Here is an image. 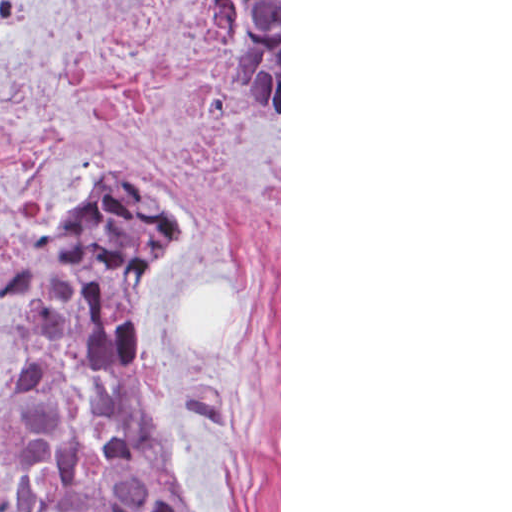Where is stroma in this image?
Segmentation results:
<instances>
[{
  "label": "stroma",
  "instance_id": "obj_1",
  "mask_svg": "<svg viewBox=\"0 0 512 512\" xmlns=\"http://www.w3.org/2000/svg\"><path fill=\"white\" fill-rule=\"evenodd\" d=\"M0 1H32L0 32V222L162 184L182 249L130 301L151 417L196 512H281V0ZM210 1H279V128L242 104ZM33 374L0 306V402Z\"/></svg>",
  "mask_w": 512,
  "mask_h": 512
}]
</instances>
